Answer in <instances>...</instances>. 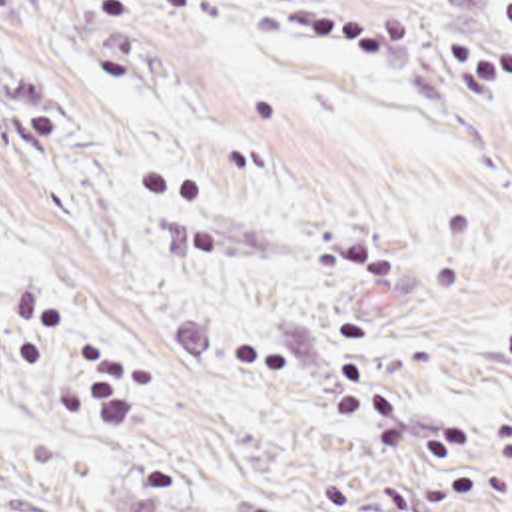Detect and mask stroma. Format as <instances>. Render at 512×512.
<instances>
[{"label":"stroma","instance_id":"obj_1","mask_svg":"<svg viewBox=\"0 0 512 512\" xmlns=\"http://www.w3.org/2000/svg\"><path fill=\"white\" fill-rule=\"evenodd\" d=\"M504 2L0 0V512H512Z\"/></svg>","mask_w":512,"mask_h":512}]
</instances>
